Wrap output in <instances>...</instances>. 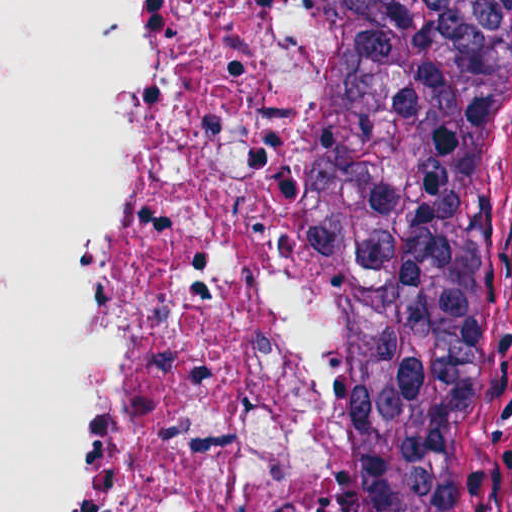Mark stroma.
<instances>
[{"instance_id":"1","label":"stroma","mask_w":512,"mask_h":512,"mask_svg":"<svg viewBox=\"0 0 512 512\" xmlns=\"http://www.w3.org/2000/svg\"><path fill=\"white\" fill-rule=\"evenodd\" d=\"M433 512H512V33L499 159Z\"/></svg>"}]
</instances>
